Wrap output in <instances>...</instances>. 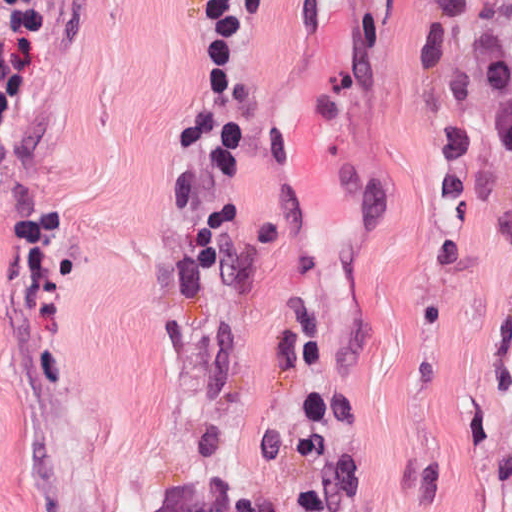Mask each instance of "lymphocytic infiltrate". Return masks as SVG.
<instances>
[{
	"label": "lymphocytic infiltrate",
	"instance_id": "1",
	"mask_svg": "<svg viewBox=\"0 0 512 512\" xmlns=\"http://www.w3.org/2000/svg\"><path fill=\"white\" fill-rule=\"evenodd\" d=\"M269 0H210L198 9L200 62L193 94L172 127L164 203L186 238L195 288L214 279L236 209L204 203L238 168L243 137V67ZM46 106V0H0V165L31 142Z\"/></svg>",
	"mask_w": 512,
	"mask_h": 512
}]
</instances>
